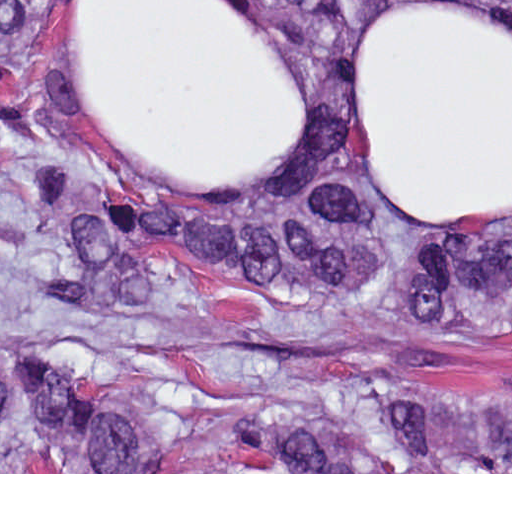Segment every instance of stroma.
<instances>
[{
	"label": "stroma",
	"mask_w": 512,
	"mask_h": 512,
	"mask_svg": "<svg viewBox=\"0 0 512 512\" xmlns=\"http://www.w3.org/2000/svg\"><path fill=\"white\" fill-rule=\"evenodd\" d=\"M79 0H56L44 69L56 118L37 152L1 140L0 0V474H512V472H1V355L45 352L83 377L143 429H175L224 415L237 401L268 389H334L372 378L428 381L472 397L512 394V329L418 327L381 317L396 292L399 263L432 223H512V206L459 222L404 212L371 169L355 105L352 49L378 12L408 0H367L339 48L345 95V170L388 254L343 300L281 287L219 282L152 260L151 295L112 312L73 307L44 292L63 245L26 201L20 171L36 166L71 188L107 192L170 209L246 214L322 182L318 161L327 126L325 88L278 0H236L281 52L304 88V136L271 173L241 193H199L144 176L114 158L72 102L65 62ZM512 23V0H451Z\"/></svg>",
	"instance_id": "stroma-1"
}]
</instances>
